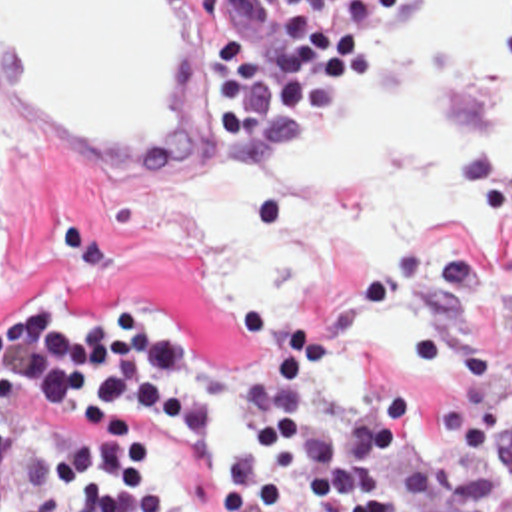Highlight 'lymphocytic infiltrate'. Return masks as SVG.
<instances>
[{"mask_svg": "<svg viewBox=\"0 0 512 512\" xmlns=\"http://www.w3.org/2000/svg\"><path fill=\"white\" fill-rule=\"evenodd\" d=\"M413 1L293 0L265 49L219 33L207 87L225 125L217 165H251L325 125L347 89L379 71ZM247 329L271 359L245 390L247 426L215 512H421L447 494L437 452L397 476L409 404L377 357L333 418L309 410L325 369L317 335L279 323L269 303L247 309ZM197 359L199 345L147 305H109L79 323L37 299L0 323V512H197L153 478V422H209L205 390L177 380Z\"/></svg>", "mask_w": 512, "mask_h": 512, "instance_id": "lymphocytic-infiltrate-1", "label": "lymphocytic infiltrate"}]
</instances>
